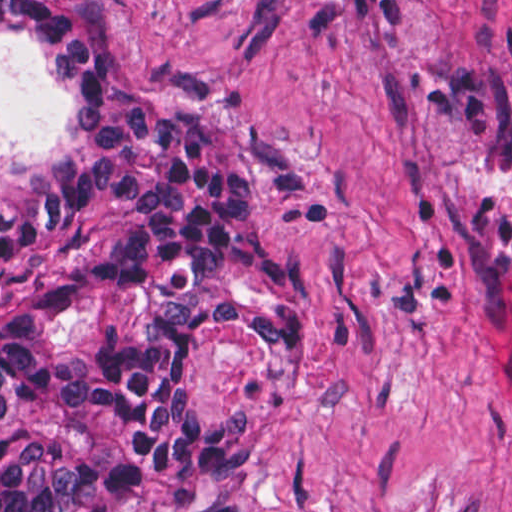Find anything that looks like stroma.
I'll return each instance as SVG.
<instances>
[{
  "label": "stroma",
  "instance_id": "obj_1",
  "mask_svg": "<svg viewBox=\"0 0 512 512\" xmlns=\"http://www.w3.org/2000/svg\"><path fill=\"white\" fill-rule=\"evenodd\" d=\"M168 107L296 144L274 244L318 346L191 339L205 421L249 427L246 512H512V0H75ZM0 39V184L71 143Z\"/></svg>",
  "mask_w": 512,
  "mask_h": 512
}]
</instances>
